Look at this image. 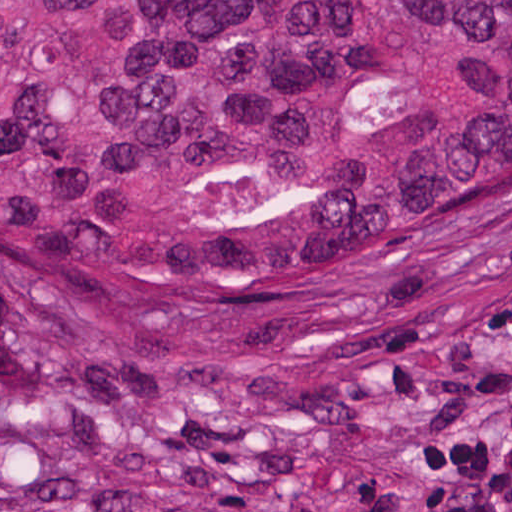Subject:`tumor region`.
<instances>
[{
	"label": "tumor region",
	"mask_w": 512,
	"mask_h": 512,
	"mask_svg": "<svg viewBox=\"0 0 512 512\" xmlns=\"http://www.w3.org/2000/svg\"><path fill=\"white\" fill-rule=\"evenodd\" d=\"M512 222V0H0V287L206 331Z\"/></svg>",
	"instance_id": "1"
}]
</instances>
